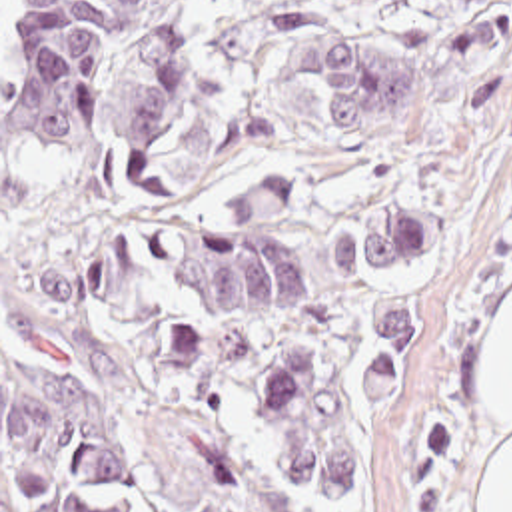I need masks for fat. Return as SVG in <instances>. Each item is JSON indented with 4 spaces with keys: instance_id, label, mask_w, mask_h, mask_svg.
<instances>
[{
    "instance_id": "fat-1",
    "label": "fat",
    "mask_w": 512,
    "mask_h": 512,
    "mask_svg": "<svg viewBox=\"0 0 512 512\" xmlns=\"http://www.w3.org/2000/svg\"><path fill=\"white\" fill-rule=\"evenodd\" d=\"M483 368L487 408L493 421L505 427V441L489 475L481 512H512V296L491 316Z\"/></svg>"
}]
</instances>
